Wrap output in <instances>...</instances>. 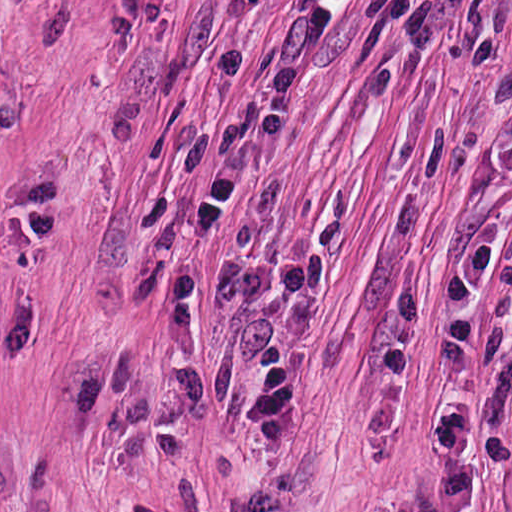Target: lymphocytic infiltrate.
Masks as SVG:
<instances>
[{"mask_svg": "<svg viewBox=\"0 0 512 512\" xmlns=\"http://www.w3.org/2000/svg\"><path fill=\"white\" fill-rule=\"evenodd\" d=\"M378 8L380 42L404 54L432 55L443 44L454 0H378ZM442 285L446 295L433 340L452 385L430 430L443 475L414 512H463L474 463L470 403L484 350L480 306L483 294L496 288L512 309V238L503 242L490 231L467 239L447 259Z\"/></svg>", "mask_w": 512, "mask_h": 512, "instance_id": "lymphocytic-infiltrate-1", "label": "lymphocytic infiltrate"}]
</instances>
